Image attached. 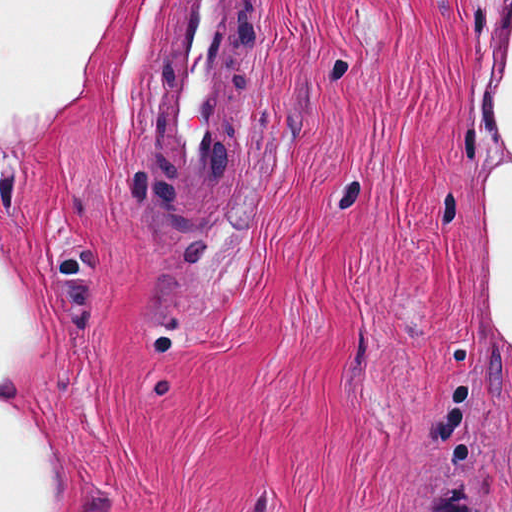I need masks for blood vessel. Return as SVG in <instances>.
<instances>
[{
	"mask_svg": "<svg viewBox=\"0 0 512 512\" xmlns=\"http://www.w3.org/2000/svg\"><path fill=\"white\" fill-rule=\"evenodd\" d=\"M251 168V0H179L148 154V197L183 234L210 231Z\"/></svg>",
	"mask_w": 512,
	"mask_h": 512,
	"instance_id": "blood-vessel-1",
	"label": "blood vessel"
}]
</instances>
